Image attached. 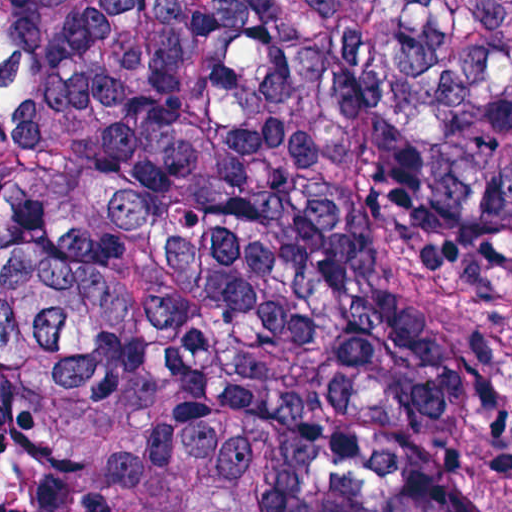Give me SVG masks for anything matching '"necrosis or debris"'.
Returning a JSON list of instances; mask_svg holds the SVG:
<instances>
[{
	"mask_svg": "<svg viewBox=\"0 0 512 512\" xmlns=\"http://www.w3.org/2000/svg\"><path fill=\"white\" fill-rule=\"evenodd\" d=\"M105 0H0V252L9 233L24 129L57 43ZM0 512H24L16 424L0 378Z\"/></svg>",
	"mask_w": 512,
	"mask_h": 512,
	"instance_id": "obj_1",
	"label": "necrosis or debris"
}]
</instances>
